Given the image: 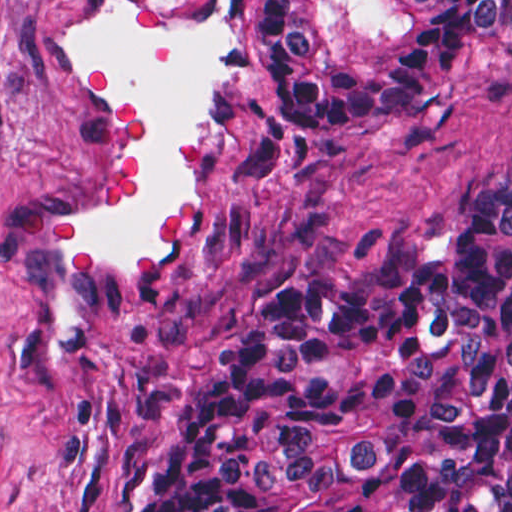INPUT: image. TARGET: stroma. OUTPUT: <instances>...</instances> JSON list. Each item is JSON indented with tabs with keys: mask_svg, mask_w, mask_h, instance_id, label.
Returning a JSON list of instances; mask_svg holds the SVG:
<instances>
[{
	"mask_svg": "<svg viewBox=\"0 0 512 512\" xmlns=\"http://www.w3.org/2000/svg\"><path fill=\"white\" fill-rule=\"evenodd\" d=\"M98 0H0V512H133L239 328L287 283L376 242L446 254L487 175H512V48L397 120L279 136L252 111V53L217 200L154 295L105 313L68 386L31 375L35 223L86 160L46 48Z\"/></svg>",
	"mask_w": 512,
	"mask_h": 512,
	"instance_id": "1",
	"label": "stroma"
}]
</instances>
